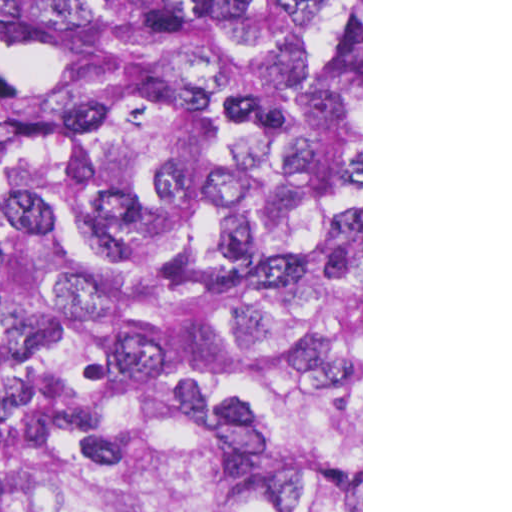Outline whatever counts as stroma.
Segmentation results:
<instances>
[{"label":"stroma","mask_w":512,"mask_h":512,"mask_svg":"<svg viewBox=\"0 0 512 512\" xmlns=\"http://www.w3.org/2000/svg\"><path fill=\"white\" fill-rule=\"evenodd\" d=\"M361 19V512H363V0H337L310 27Z\"/></svg>","instance_id":"stroma-1"}]
</instances>
